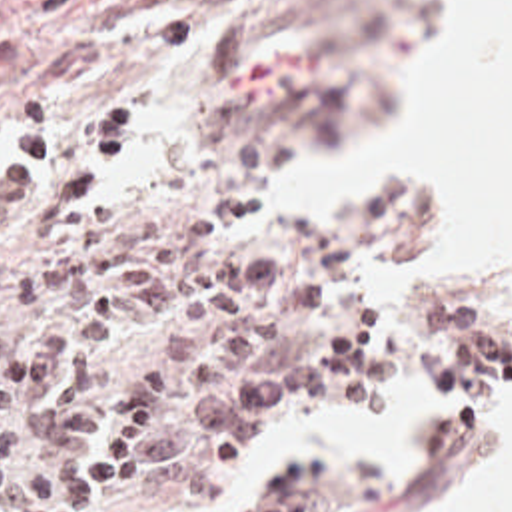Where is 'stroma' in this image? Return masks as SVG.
<instances>
[{"label": "stroma", "instance_id": "35a3bbf8", "mask_svg": "<svg viewBox=\"0 0 512 512\" xmlns=\"http://www.w3.org/2000/svg\"><path fill=\"white\" fill-rule=\"evenodd\" d=\"M450 0H0L1 21L23 33V65L0 91V163L13 147V117L46 101L64 135V167L94 117L126 107L138 145L102 199L110 235L138 219L204 223L238 191L260 199V181L344 147L374 129L392 91L376 85L386 63L430 29ZM444 211H426L414 189L392 187L328 213H274L222 249L272 259L306 243L354 255V273L326 303L278 321L268 345L324 339L374 311V349L352 380L294 392L262 406L234 442L210 454L186 412L188 444L172 462L136 478L108 512H160L188 474L216 464L280 404L342 394L376 363L400 355L482 400L512 398V307L490 301L484 267L410 297L360 289L364 269L432 233ZM1 229V217H0ZM494 434L462 420L410 450L330 456L256 512H396L448 464Z\"/></svg>", "mask_w": 512, "mask_h": 512}]
</instances>
